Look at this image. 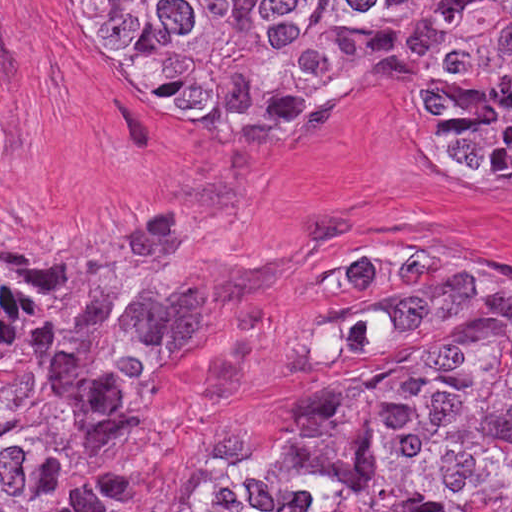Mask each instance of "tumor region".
Instances as JSON below:
<instances>
[{
    "mask_svg": "<svg viewBox=\"0 0 512 512\" xmlns=\"http://www.w3.org/2000/svg\"><path fill=\"white\" fill-rule=\"evenodd\" d=\"M68 46L167 126L233 145L405 58L424 159L512 177V0H54ZM219 213L163 218L45 284L0 272V512H101L128 354L213 281ZM192 512H512V282L403 240L343 264L240 388Z\"/></svg>",
    "mask_w": 512,
    "mask_h": 512,
    "instance_id": "1",
    "label": "tumor region"
}]
</instances>
